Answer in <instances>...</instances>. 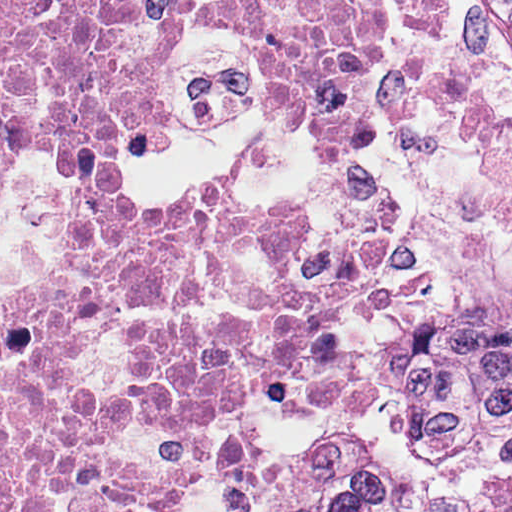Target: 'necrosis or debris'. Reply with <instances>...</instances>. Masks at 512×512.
<instances>
[{"label": "necrosis or debris", "instance_id": "1", "mask_svg": "<svg viewBox=\"0 0 512 512\" xmlns=\"http://www.w3.org/2000/svg\"><path fill=\"white\" fill-rule=\"evenodd\" d=\"M440 0H0V512H260L381 417L437 275L369 143Z\"/></svg>", "mask_w": 512, "mask_h": 512}]
</instances>
